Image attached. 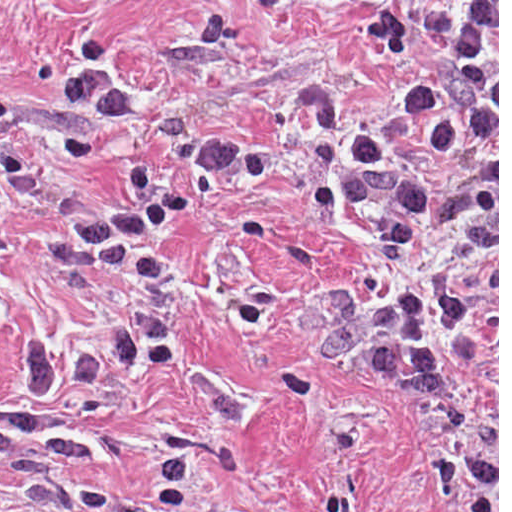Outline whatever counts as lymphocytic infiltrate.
<instances>
[{"mask_svg":"<svg viewBox=\"0 0 512 512\" xmlns=\"http://www.w3.org/2000/svg\"><path fill=\"white\" fill-rule=\"evenodd\" d=\"M186 222L184 201L158 187L151 168L130 163L128 191L121 201L91 206L47 242L56 257L120 272L147 285H160L166 269L146 251Z\"/></svg>","mask_w":512,"mask_h":512,"instance_id":"obj_1","label":"lymphocytic infiltrate"}]
</instances>
